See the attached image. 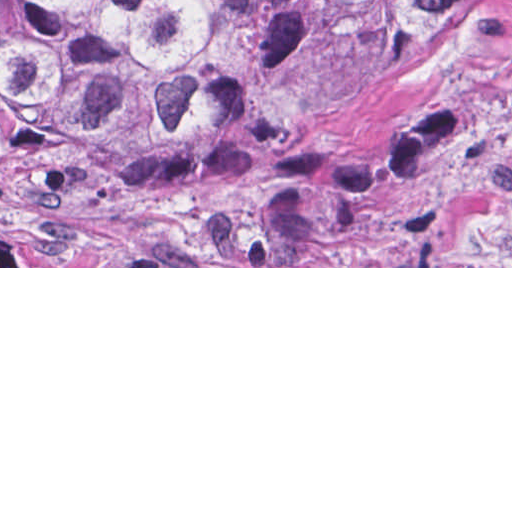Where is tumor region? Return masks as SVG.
I'll use <instances>...</instances> for the list:
<instances>
[{"instance_id":"tumor-region-1","label":"tumor region","mask_w":512,"mask_h":512,"mask_svg":"<svg viewBox=\"0 0 512 512\" xmlns=\"http://www.w3.org/2000/svg\"><path fill=\"white\" fill-rule=\"evenodd\" d=\"M449 0H0V266H255Z\"/></svg>"}]
</instances>
